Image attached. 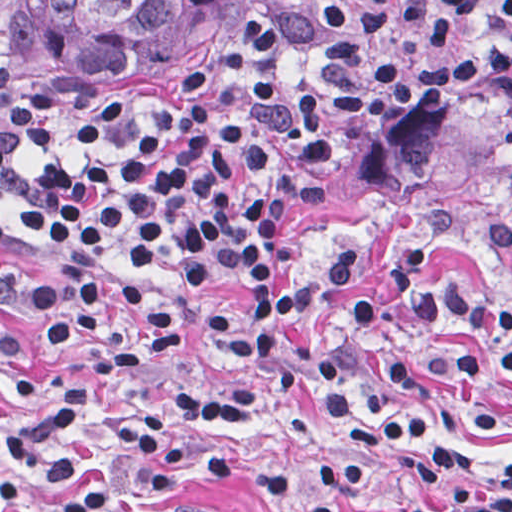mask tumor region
Here are the masks:
<instances>
[{
    "label": "tumor region",
    "mask_w": 512,
    "mask_h": 512,
    "mask_svg": "<svg viewBox=\"0 0 512 512\" xmlns=\"http://www.w3.org/2000/svg\"><path fill=\"white\" fill-rule=\"evenodd\" d=\"M250 0H0V35L77 95L116 99L211 44Z\"/></svg>",
    "instance_id": "e687c5a6"
}]
</instances>
